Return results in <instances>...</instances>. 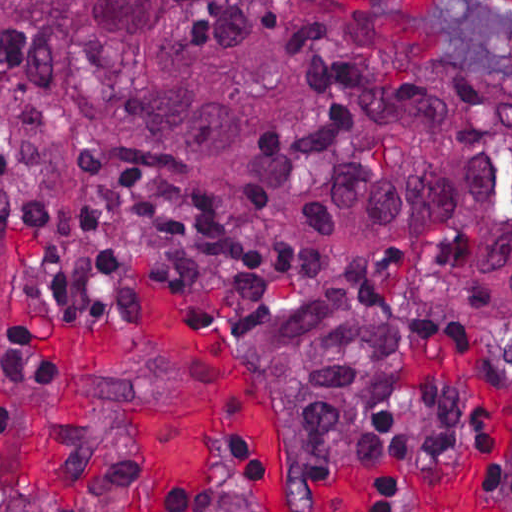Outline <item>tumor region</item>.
<instances>
[{
    "instance_id": "1",
    "label": "tumor region",
    "mask_w": 512,
    "mask_h": 512,
    "mask_svg": "<svg viewBox=\"0 0 512 512\" xmlns=\"http://www.w3.org/2000/svg\"><path fill=\"white\" fill-rule=\"evenodd\" d=\"M0 121L52 168L187 192L351 257L259 328L290 446L394 469L470 439L409 382L431 323L512 325V89L301 0H0Z\"/></svg>"
}]
</instances>
